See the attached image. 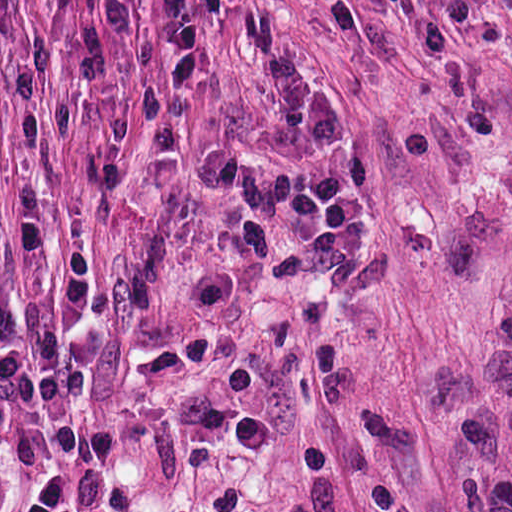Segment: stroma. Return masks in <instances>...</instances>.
<instances>
[{
	"label": "stroma",
	"instance_id": "1",
	"mask_svg": "<svg viewBox=\"0 0 512 512\" xmlns=\"http://www.w3.org/2000/svg\"><path fill=\"white\" fill-rule=\"evenodd\" d=\"M0 213L75 512H512V0H0Z\"/></svg>",
	"mask_w": 512,
	"mask_h": 512
}]
</instances>
